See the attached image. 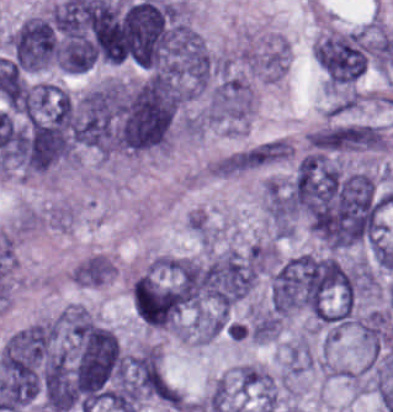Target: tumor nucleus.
<instances>
[{"instance_id":"tumor-nucleus-2","label":"tumor nucleus","mask_w":393,"mask_h":412,"mask_svg":"<svg viewBox=\"0 0 393 412\" xmlns=\"http://www.w3.org/2000/svg\"><path fill=\"white\" fill-rule=\"evenodd\" d=\"M256 280L246 251L227 248L204 259L200 294L230 309L251 292Z\"/></svg>"},{"instance_id":"tumor-nucleus-1","label":"tumor nucleus","mask_w":393,"mask_h":412,"mask_svg":"<svg viewBox=\"0 0 393 412\" xmlns=\"http://www.w3.org/2000/svg\"><path fill=\"white\" fill-rule=\"evenodd\" d=\"M209 263L179 257L132 277L134 307L148 325L176 327L201 300Z\"/></svg>"}]
</instances>
